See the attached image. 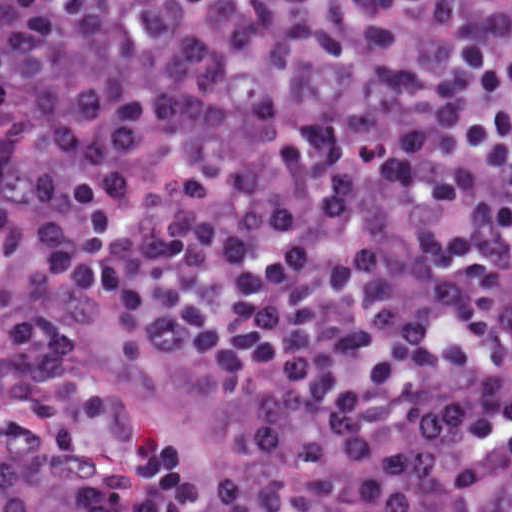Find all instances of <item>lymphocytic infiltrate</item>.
I'll return each mask as SVG.
<instances>
[{"label":"lymphocytic infiltrate","mask_w":512,"mask_h":512,"mask_svg":"<svg viewBox=\"0 0 512 512\" xmlns=\"http://www.w3.org/2000/svg\"><path fill=\"white\" fill-rule=\"evenodd\" d=\"M62 289L218 374L228 478ZM0 512H512V0H0Z\"/></svg>","instance_id":"1"}]
</instances>
